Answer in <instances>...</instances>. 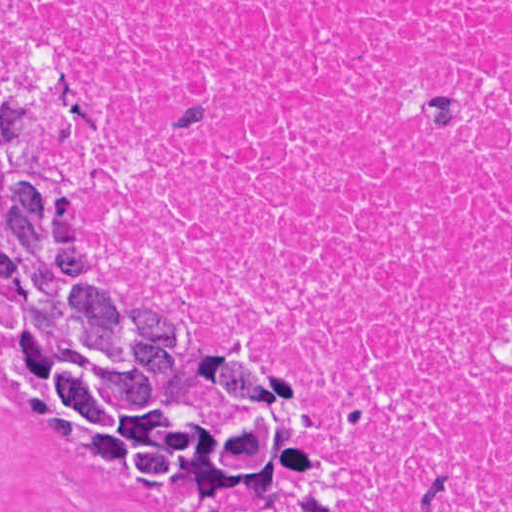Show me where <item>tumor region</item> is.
<instances>
[{"label": "tumor region", "instance_id": "tumor-region-1", "mask_svg": "<svg viewBox=\"0 0 512 512\" xmlns=\"http://www.w3.org/2000/svg\"><path fill=\"white\" fill-rule=\"evenodd\" d=\"M85 117L62 28L36 18L0 61V381L69 459L177 512H341L292 358L188 342L166 298L91 273L86 214L40 167Z\"/></svg>", "mask_w": 512, "mask_h": 512}]
</instances>
